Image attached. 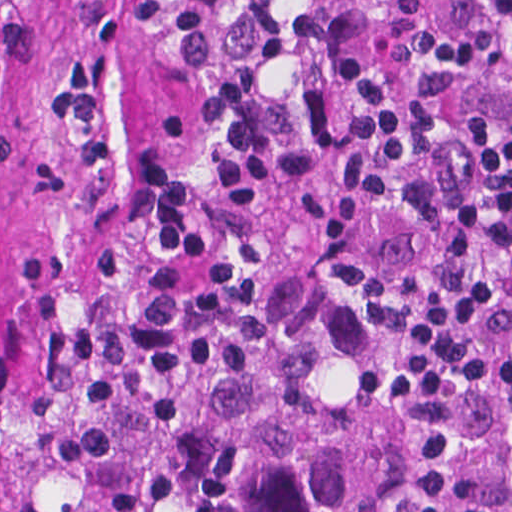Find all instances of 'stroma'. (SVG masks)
<instances>
[{"label": "stroma", "mask_w": 512, "mask_h": 512, "mask_svg": "<svg viewBox=\"0 0 512 512\" xmlns=\"http://www.w3.org/2000/svg\"><path fill=\"white\" fill-rule=\"evenodd\" d=\"M449 0H384L383 35L421 23L435 16ZM374 353L370 366L377 363V334L372 322Z\"/></svg>", "instance_id": "stroma-1"}]
</instances>
